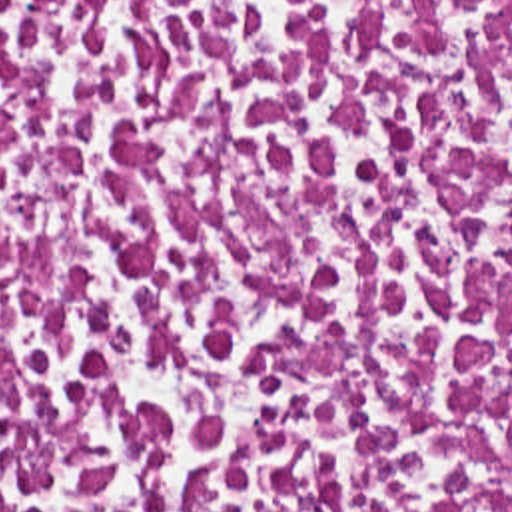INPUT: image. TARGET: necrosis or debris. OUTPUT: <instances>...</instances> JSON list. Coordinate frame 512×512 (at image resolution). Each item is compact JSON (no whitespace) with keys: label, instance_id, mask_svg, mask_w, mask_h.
<instances>
[{"label":"necrosis or debris","instance_id":"obj_1","mask_svg":"<svg viewBox=\"0 0 512 512\" xmlns=\"http://www.w3.org/2000/svg\"><path fill=\"white\" fill-rule=\"evenodd\" d=\"M0 512H512V0H0Z\"/></svg>","mask_w":512,"mask_h":512}]
</instances>
